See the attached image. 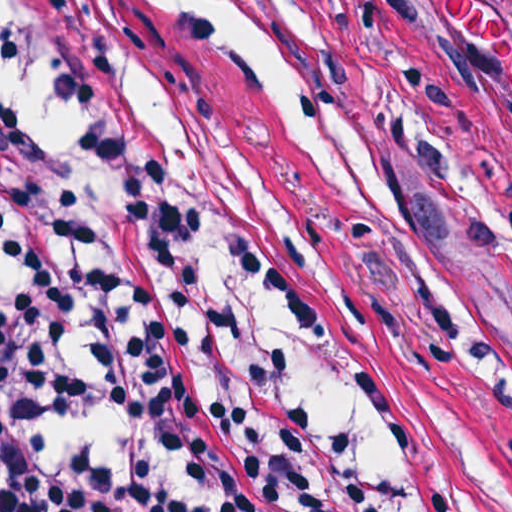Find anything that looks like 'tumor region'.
Returning <instances> with one entry per match:
<instances>
[{"label":"tumor region","instance_id":"1","mask_svg":"<svg viewBox=\"0 0 512 512\" xmlns=\"http://www.w3.org/2000/svg\"><path fill=\"white\" fill-rule=\"evenodd\" d=\"M494 160L499 192L472 197L512 245V0H373Z\"/></svg>","mask_w":512,"mask_h":512}]
</instances>
